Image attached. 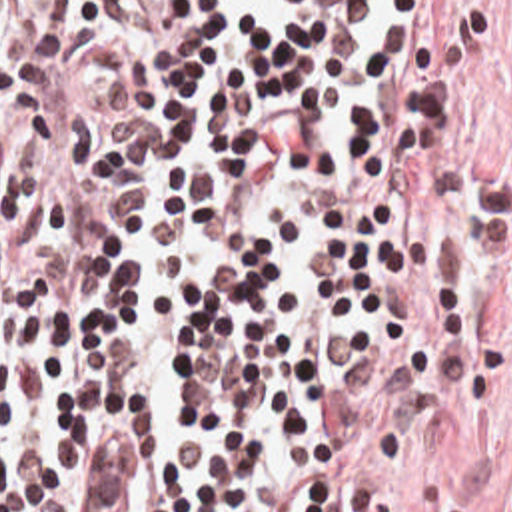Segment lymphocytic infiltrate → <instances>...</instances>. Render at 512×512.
I'll return each mask as SVG.
<instances>
[{
	"instance_id": "lymphocytic-infiltrate-1",
	"label": "lymphocytic infiltrate",
	"mask_w": 512,
	"mask_h": 512,
	"mask_svg": "<svg viewBox=\"0 0 512 512\" xmlns=\"http://www.w3.org/2000/svg\"><path fill=\"white\" fill-rule=\"evenodd\" d=\"M461 0H0V512H366L491 242Z\"/></svg>"
}]
</instances>
